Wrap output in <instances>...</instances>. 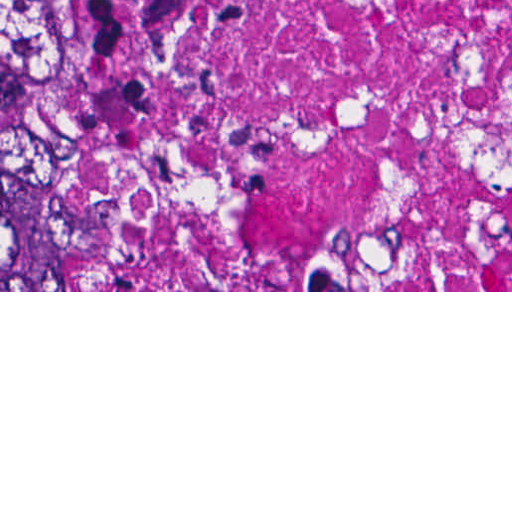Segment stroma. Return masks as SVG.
Instances as JSON below:
<instances>
[{
    "label": "stroma",
    "mask_w": 512,
    "mask_h": 512,
    "mask_svg": "<svg viewBox=\"0 0 512 512\" xmlns=\"http://www.w3.org/2000/svg\"><path fill=\"white\" fill-rule=\"evenodd\" d=\"M33 114H59L75 127L84 121L86 133L103 187L116 173L112 155L98 136L94 113H0V127L13 119ZM0 292H512V290H334L322 282L308 290H148L138 273L113 242V274L94 291H0Z\"/></svg>",
    "instance_id": "stroma-1"
}]
</instances>
